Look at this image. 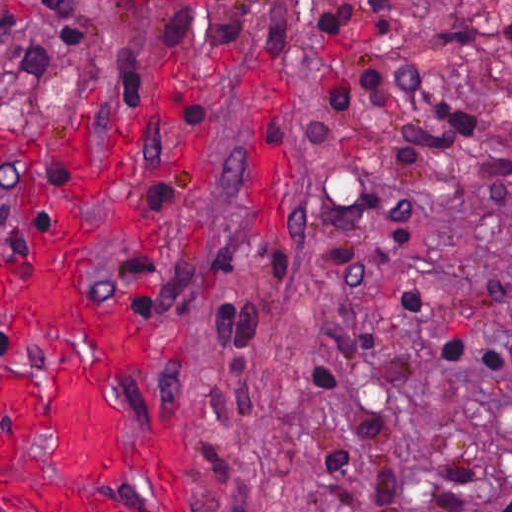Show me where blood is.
I'll list each match as a JSON object with an SVG mask.
<instances>
[{
    "mask_svg": "<svg viewBox=\"0 0 512 512\" xmlns=\"http://www.w3.org/2000/svg\"><path fill=\"white\" fill-rule=\"evenodd\" d=\"M159 210L141 134L57 145L0 284V508L200 512V441L150 392L160 307L100 262L153 247Z\"/></svg>",
    "mask_w": 512,
    "mask_h": 512,
    "instance_id": "blood-1",
    "label": "blood"
}]
</instances>
